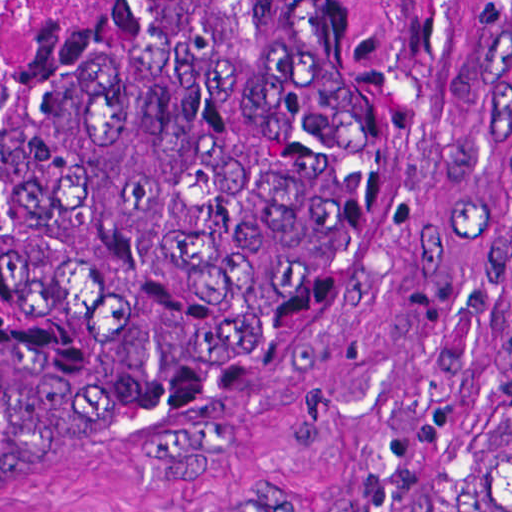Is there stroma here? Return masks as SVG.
Wrapping results in <instances>:
<instances>
[{"label":"stroma","mask_w":512,"mask_h":512,"mask_svg":"<svg viewBox=\"0 0 512 512\" xmlns=\"http://www.w3.org/2000/svg\"><path fill=\"white\" fill-rule=\"evenodd\" d=\"M61 0L0 57V92ZM512 388V0L454 159L302 349L142 465L0 512H447Z\"/></svg>","instance_id":"1"}]
</instances>
